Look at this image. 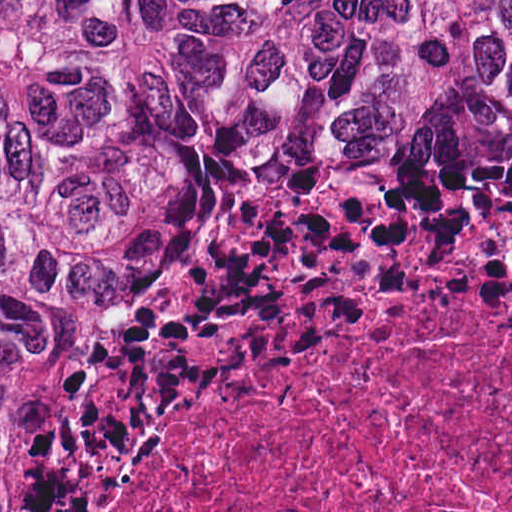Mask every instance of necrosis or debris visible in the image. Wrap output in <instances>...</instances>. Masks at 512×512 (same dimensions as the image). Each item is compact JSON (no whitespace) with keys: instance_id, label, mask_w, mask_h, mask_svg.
Returning a JSON list of instances; mask_svg holds the SVG:
<instances>
[{"instance_id":"obj_1","label":"necrosis or debris","mask_w":512,"mask_h":512,"mask_svg":"<svg viewBox=\"0 0 512 512\" xmlns=\"http://www.w3.org/2000/svg\"><path fill=\"white\" fill-rule=\"evenodd\" d=\"M137 512H512V281H407L273 340Z\"/></svg>"}]
</instances>
